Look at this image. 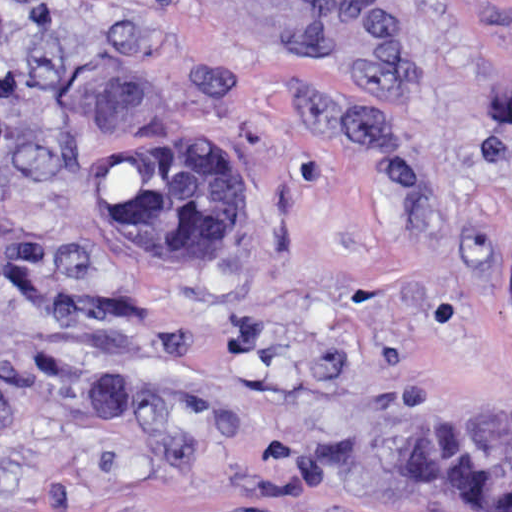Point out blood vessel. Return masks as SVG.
Segmentation results:
<instances>
[{
    "instance_id": "obj_1",
    "label": "blood vessel",
    "mask_w": 512,
    "mask_h": 512,
    "mask_svg": "<svg viewBox=\"0 0 512 512\" xmlns=\"http://www.w3.org/2000/svg\"><path fill=\"white\" fill-rule=\"evenodd\" d=\"M239 19L303 36L336 29L347 0H203Z\"/></svg>"
}]
</instances>
